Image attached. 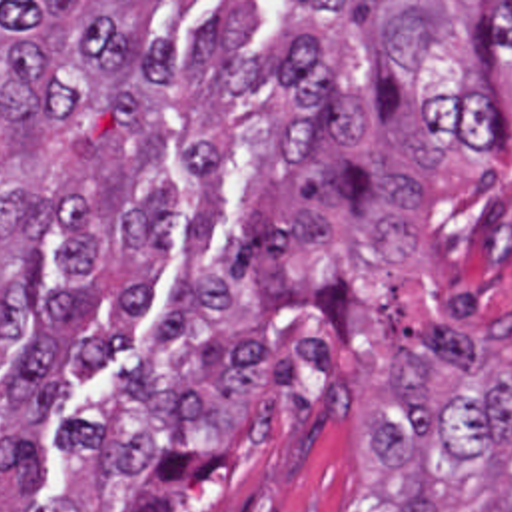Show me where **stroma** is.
Returning a JSON list of instances; mask_svg holds the SVG:
<instances>
[{
  "label": "stroma",
  "mask_w": 512,
  "mask_h": 512,
  "mask_svg": "<svg viewBox=\"0 0 512 512\" xmlns=\"http://www.w3.org/2000/svg\"><path fill=\"white\" fill-rule=\"evenodd\" d=\"M104 2L142 32L176 38L162 104L176 152L144 170L148 194L176 178L168 236L176 248L98 266L90 289L148 277L130 345L66 371L40 431V469L18 493L0 471V512H398L372 475L382 417L404 427L390 351L412 347L374 293L368 208L340 218L320 254L280 268L314 283L342 271L356 339L342 345L310 305L260 295L232 250L246 184L294 120L272 58L296 38L286 2H460L512 40V0H0ZM28 234L0 238V275ZM16 365L30 321L2 343ZM12 415L0 391V421Z\"/></svg>",
  "instance_id": "1"
}]
</instances>
